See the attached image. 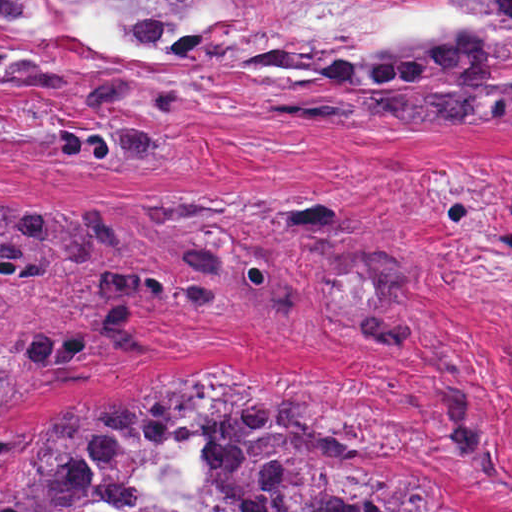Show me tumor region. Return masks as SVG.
Here are the masks:
<instances>
[{
  "mask_svg": "<svg viewBox=\"0 0 512 512\" xmlns=\"http://www.w3.org/2000/svg\"><path fill=\"white\" fill-rule=\"evenodd\" d=\"M254 1L0 0V88L13 92L0 94L88 102L102 122L62 130L50 154L157 172L160 145L121 117L213 50L174 100ZM466 2L455 35L350 40L299 0H265L214 92L234 118L512 106V0ZM439 284L398 226L322 194L146 212L0 188V512H169L138 505L136 483L178 450L213 483L216 512H449L335 442L297 389L224 355L187 387L10 430L44 387L146 353L148 326L170 312L244 316L290 292L430 357L472 487L509 501V471L473 414V356L426 301Z\"/></svg>",
  "mask_w": 512,
  "mask_h": 512,
  "instance_id": "1",
  "label": "tumor region"
}]
</instances>
